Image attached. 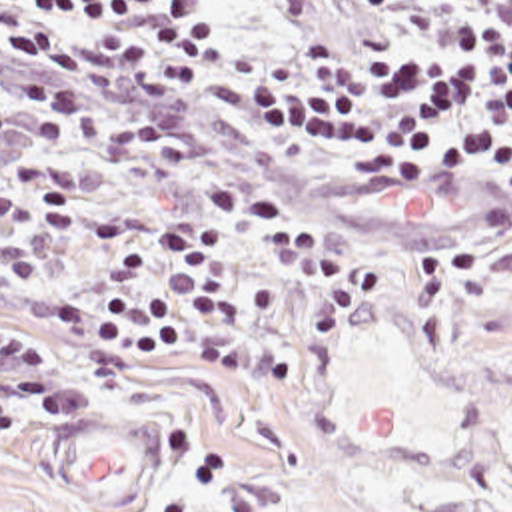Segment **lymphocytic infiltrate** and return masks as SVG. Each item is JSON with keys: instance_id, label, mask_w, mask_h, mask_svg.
Segmentation results:
<instances>
[{"instance_id": "lymphocytic-infiltrate-1", "label": "lymphocytic infiltrate", "mask_w": 512, "mask_h": 512, "mask_svg": "<svg viewBox=\"0 0 512 512\" xmlns=\"http://www.w3.org/2000/svg\"><path fill=\"white\" fill-rule=\"evenodd\" d=\"M0 74L30 112L0 106V136L78 140L136 162H182L190 140L160 120L96 112L80 86L126 102L180 96L204 114L274 136L348 186L421 178L409 30L356 24L324 44L250 56L238 0H0ZM0 190V290L28 286L76 218V182L54 162L16 160ZM200 208L140 200L94 206L82 246L92 276L50 302L48 332L74 349L80 391L150 383L226 314L228 230L318 280L290 334L210 332L202 363L260 391L296 389L316 347L378 280L372 252L270 192L212 184ZM0 449L26 417L60 423L76 387L54 345L0 320Z\"/></svg>"}]
</instances>
